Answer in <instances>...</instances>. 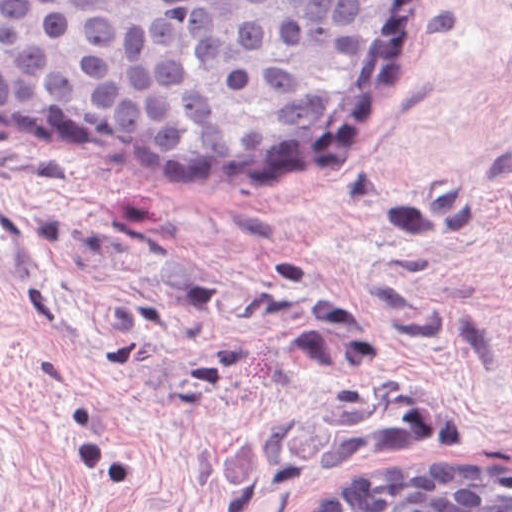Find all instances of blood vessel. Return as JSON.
<instances>
[{
    "instance_id": "blood-vessel-1",
    "label": "blood vessel",
    "mask_w": 512,
    "mask_h": 512,
    "mask_svg": "<svg viewBox=\"0 0 512 512\" xmlns=\"http://www.w3.org/2000/svg\"><path fill=\"white\" fill-rule=\"evenodd\" d=\"M512 12V0H508ZM48 267V242L38 222L0 197V283H25Z\"/></svg>"
}]
</instances>
